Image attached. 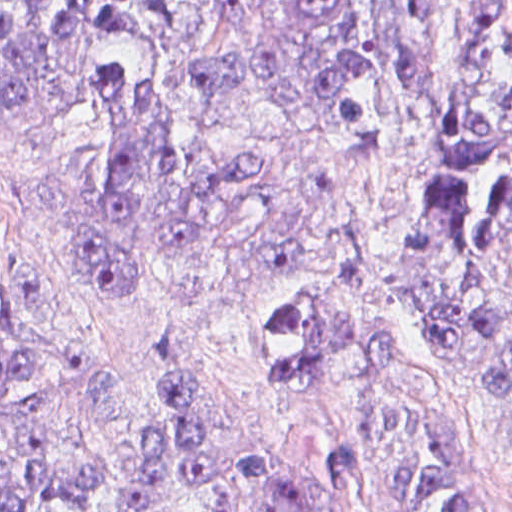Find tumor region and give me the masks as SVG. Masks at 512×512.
<instances>
[{
    "mask_svg": "<svg viewBox=\"0 0 512 512\" xmlns=\"http://www.w3.org/2000/svg\"><path fill=\"white\" fill-rule=\"evenodd\" d=\"M440 0H0V142L86 133L80 270L258 260L308 205L273 154L201 145L225 108L347 140L427 92ZM390 304L512 420V0L475 19L404 265L294 270ZM243 351L319 398L334 488L380 512H488L450 454L427 343L395 320L252 315ZM308 512L275 452L220 419L183 340L118 360L0 339V512Z\"/></svg>",
    "mask_w": 512,
    "mask_h": 512,
    "instance_id": "obj_1",
    "label": "tumor region"
}]
</instances>
